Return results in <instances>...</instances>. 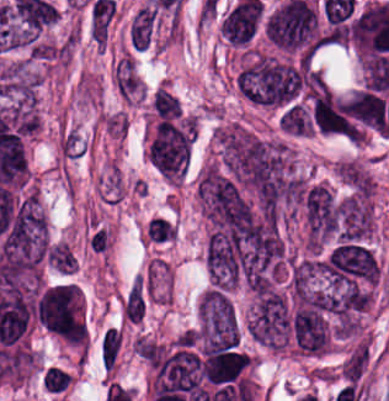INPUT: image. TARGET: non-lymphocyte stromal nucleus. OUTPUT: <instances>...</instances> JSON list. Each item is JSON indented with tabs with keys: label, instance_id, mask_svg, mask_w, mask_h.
<instances>
[{
	"label": "non-lymphocyte stromal nucleus",
	"instance_id": "obj_3",
	"mask_svg": "<svg viewBox=\"0 0 389 401\" xmlns=\"http://www.w3.org/2000/svg\"><path fill=\"white\" fill-rule=\"evenodd\" d=\"M150 107L157 121L181 120L183 107L181 99L164 85H157L150 94Z\"/></svg>",
	"mask_w": 389,
	"mask_h": 401
},
{
	"label": "non-lymphocyte stromal nucleus",
	"instance_id": "obj_4",
	"mask_svg": "<svg viewBox=\"0 0 389 401\" xmlns=\"http://www.w3.org/2000/svg\"><path fill=\"white\" fill-rule=\"evenodd\" d=\"M123 336L118 327H109L102 340V358L109 369H114Z\"/></svg>",
	"mask_w": 389,
	"mask_h": 401
},
{
	"label": "non-lymphocyte stromal nucleus",
	"instance_id": "obj_1",
	"mask_svg": "<svg viewBox=\"0 0 389 401\" xmlns=\"http://www.w3.org/2000/svg\"><path fill=\"white\" fill-rule=\"evenodd\" d=\"M194 116L160 119L146 147L149 161L171 182H179L191 153Z\"/></svg>",
	"mask_w": 389,
	"mask_h": 401
},
{
	"label": "non-lymphocyte stromal nucleus",
	"instance_id": "obj_2",
	"mask_svg": "<svg viewBox=\"0 0 389 401\" xmlns=\"http://www.w3.org/2000/svg\"><path fill=\"white\" fill-rule=\"evenodd\" d=\"M141 80L135 61L130 56L118 59L113 73V86L120 98L131 102L140 90Z\"/></svg>",
	"mask_w": 389,
	"mask_h": 401
},
{
	"label": "non-lymphocyte stromal nucleus",
	"instance_id": "obj_5",
	"mask_svg": "<svg viewBox=\"0 0 389 401\" xmlns=\"http://www.w3.org/2000/svg\"><path fill=\"white\" fill-rule=\"evenodd\" d=\"M145 307L141 279H134L123 308L125 317L140 319L142 318Z\"/></svg>",
	"mask_w": 389,
	"mask_h": 401
}]
</instances>
